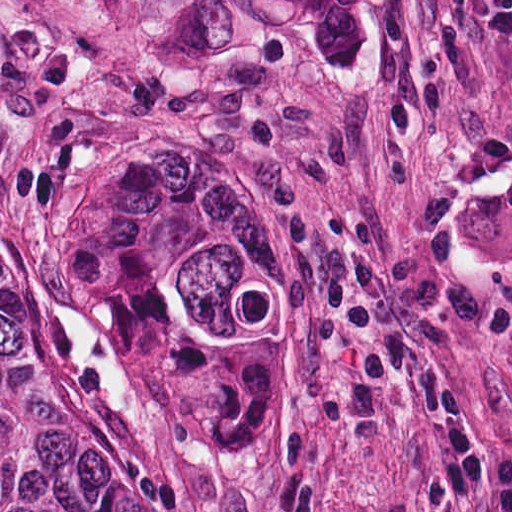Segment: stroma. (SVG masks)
Returning <instances> with one entry per match:
<instances>
[{"label":"stroma","instance_id":"obj_1","mask_svg":"<svg viewBox=\"0 0 512 512\" xmlns=\"http://www.w3.org/2000/svg\"><path fill=\"white\" fill-rule=\"evenodd\" d=\"M166 131L300 176L354 286L442 366L480 463L279 293L263 399L172 435L23 248L52 174ZM0 242L189 512H512V0H0Z\"/></svg>","mask_w":512,"mask_h":512}]
</instances>
